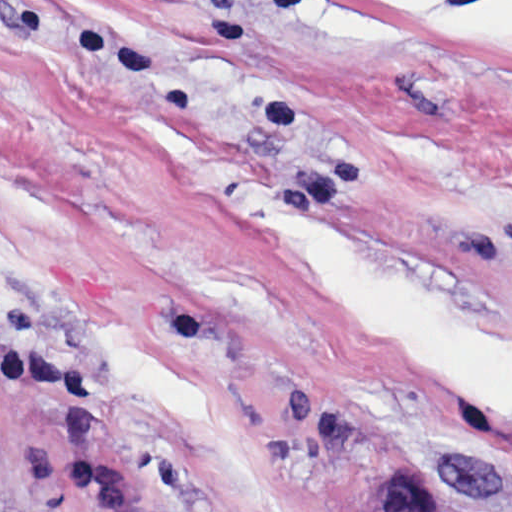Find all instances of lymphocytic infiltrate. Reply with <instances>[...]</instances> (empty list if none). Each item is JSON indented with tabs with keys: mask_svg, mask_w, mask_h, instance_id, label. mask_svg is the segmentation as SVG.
<instances>
[{
	"mask_svg": "<svg viewBox=\"0 0 512 512\" xmlns=\"http://www.w3.org/2000/svg\"><path fill=\"white\" fill-rule=\"evenodd\" d=\"M10 392L51 394L62 411L60 477L98 512H148L133 470L110 443L96 402V378L80 359L19 338L0 307V418Z\"/></svg>",
	"mask_w": 512,
	"mask_h": 512,
	"instance_id": "f902f5d3",
	"label": "lymphocytic infiltrate"
}]
</instances>
